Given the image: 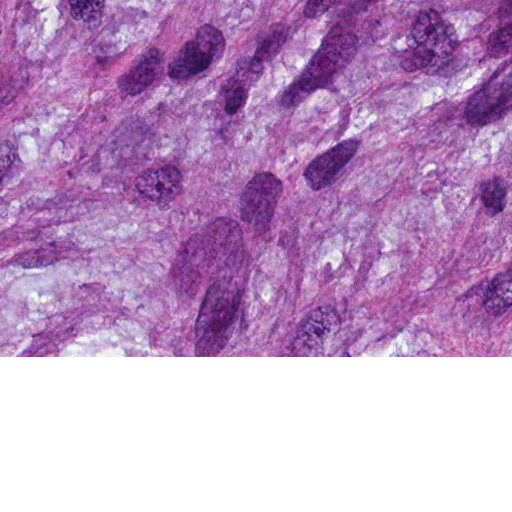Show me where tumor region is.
I'll return each mask as SVG.
<instances>
[{"label": "tumor region", "mask_w": 512, "mask_h": 512, "mask_svg": "<svg viewBox=\"0 0 512 512\" xmlns=\"http://www.w3.org/2000/svg\"><path fill=\"white\" fill-rule=\"evenodd\" d=\"M0 356H512V0H0Z\"/></svg>", "instance_id": "1"}]
</instances>
